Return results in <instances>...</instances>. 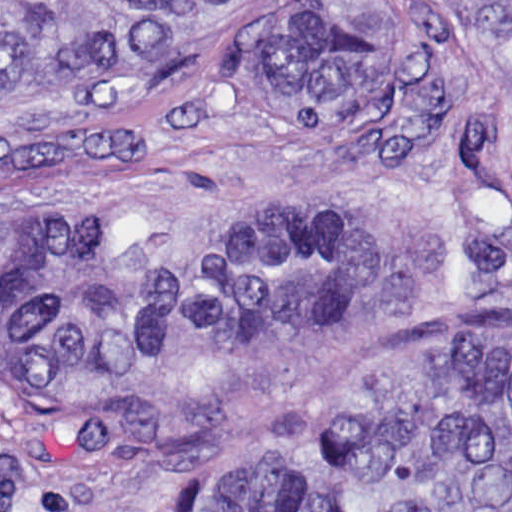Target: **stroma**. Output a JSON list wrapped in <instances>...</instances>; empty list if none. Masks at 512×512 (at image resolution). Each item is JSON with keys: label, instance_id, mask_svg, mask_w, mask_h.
Instances as JSON below:
<instances>
[{"label": "stroma", "instance_id": "1", "mask_svg": "<svg viewBox=\"0 0 512 512\" xmlns=\"http://www.w3.org/2000/svg\"><path fill=\"white\" fill-rule=\"evenodd\" d=\"M252 38L196 71L179 129L79 177L9 161L128 103L0 114V220L94 223L163 202H306L349 227L346 297L194 364L0 383V512H213L330 411L424 360L512 335V127L465 147L491 62L446 26L413 37L379 101L319 124L263 106Z\"/></svg>", "mask_w": 512, "mask_h": 512}]
</instances>
